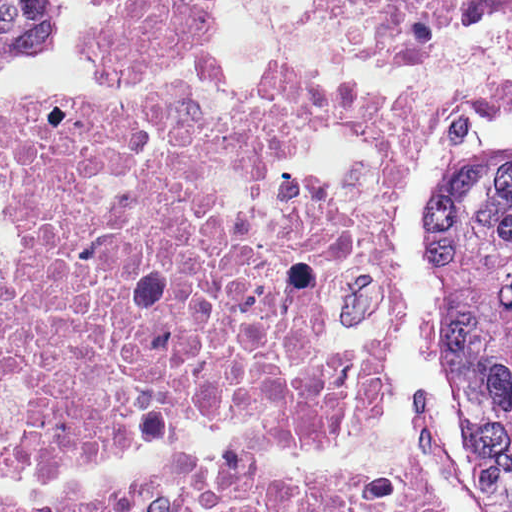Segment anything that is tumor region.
<instances>
[{"label":"tumor region","instance_id":"obj_1","mask_svg":"<svg viewBox=\"0 0 512 512\" xmlns=\"http://www.w3.org/2000/svg\"><path fill=\"white\" fill-rule=\"evenodd\" d=\"M57 0H0V64L48 51ZM425 282L452 430L497 464L512 512V142L460 141L440 153L425 198Z\"/></svg>","mask_w":512,"mask_h":512}]
</instances>
